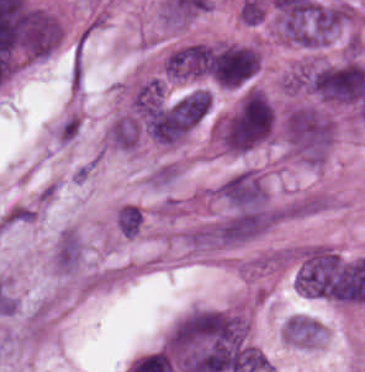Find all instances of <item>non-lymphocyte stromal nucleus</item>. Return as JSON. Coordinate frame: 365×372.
<instances>
[{
	"label": "non-lymphocyte stromal nucleus",
	"mask_w": 365,
	"mask_h": 372,
	"mask_svg": "<svg viewBox=\"0 0 365 372\" xmlns=\"http://www.w3.org/2000/svg\"><path fill=\"white\" fill-rule=\"evenodd\" d=\"M282 154L307 166L322 167L329 151L334 120L322 108L297 103L279 121Z\"/></svg>",
	"instance_id": "obj_1"
},
{
	"label": "non-lymphocyte stromal nucleus",
	"mask_w": 365,
	"mask_h": 372,
	"mask_svg": "<svg viewBox=\"0 0 365 372\" xmlns=\"http://www.w3.org/2000/svg\"><path fill=\"white\" fill-rule=\"evenodd\" d=\"M35 211L22 203H15L0 218L5 226H12L33 220Z\"/></svg>",
	"instance_id": "obj_7"
},
{
	"label": "non-lymphocyte stromal nucleus",
	"mask_w": 365,
	"mask_h": 372,
	"mask_svg": "<svg viewBox=\"0 0 365 372\" xmlns=\"http://www.w3.org/2000/svg\"><path fill=\"white\" fill-rule=\"evenodd\" d=\"M80 127V117L77 113H70L61 120L53 129L52 135L55 142L68 144L77 134Z\"/></svg>",
	"instance_id": "obj_6"
},
{
	"label": "non-lymphocyte stromal nucleus",
	"mask_w": 365,
	"mask_h": 372,
	"mask_svg": "<svg viewBox=\"0 0 365 372\" xmlns=\"http://www.w3.org/2000/svg\"><path fill=\"white\" fill-rule=\"evenodd\" d=\"M85 246L74 227H67L56 238L49 253L53 271L60 274H74L79 267Z\"/></svg>",
	"instance_id": "obj_3"
},
{
	"label": "non-lymphocyte stromal nucleus",
	"mask_w": 365,
	"mask_h": 372,
	"mask_svg": "<svg viewBox=\"0 0 365 372\" xmlns=\"http://www.w3.org/2000/svg\"><path fill=\"white\" fill-rule=\"evenodd\" d=\"M142 136V124L133 112L121 111L106 125L102 143L111 150L129 152L138 148Z\"/></svg>",
	"instance_id": "obj_2"
},
{
	"label": "non-lymphocyte stromal nucleus",
	"mask_w": 365,
	"mask_h": 372,
	"mask_svg": "<svg viewBox=\"0 0 365 372\" xmlns=\"http://www.w3.org/2000/svg\"><path fill=\"white\" fill-rule=\"evenodd\" d=\"M179 174V166L171 161H164L153 166L147 173V185L164 187L175 180Z\"/></svg>",
	"instance_id": "obj_5"
},
{
	"label": "non-lymphocyte stromal nucleus",
	"mask_w": 365,
	"mask_h": 372,
	"mask_svg": "<svg viewBox=\"0 0 365 372\" xmlns=\"http://www.w3.org/2000/svg\"><path fill=\"white\" fill-rule=\"evenodd\" d=\"M324 206L323 192L303 195L286 203L282 217L300 218L322 209Z\"/></svg>",
	"instance_id": "obj_4"
}]
</instances>
